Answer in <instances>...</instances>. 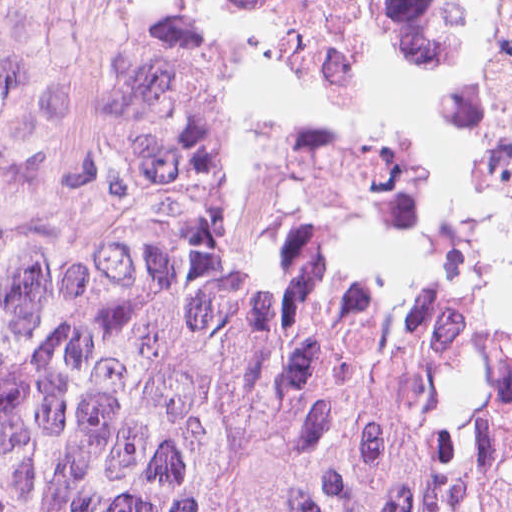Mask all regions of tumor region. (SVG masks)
<instances>
[{
	"label": "tumor region",
	"instance_id": "e687c5a6",
	"mask_svg": "<svg viewBox=\"0 0 512 512\" xmlns=\"http://www.w3.org/2000/svg\"><path fill=\"white\" fill-rule=\"evenodd\" d=\"M0 512H512V317L282 262L199 13L0 114Z\"/></svg>",
	"mask_w": 512,
	"mask_h": 512
}]
</instances>
